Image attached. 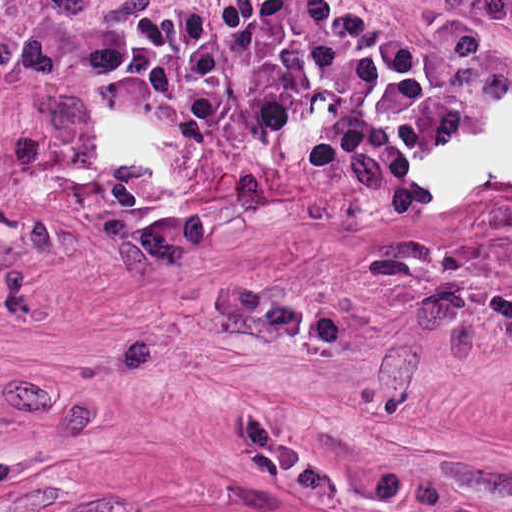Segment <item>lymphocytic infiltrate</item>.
<instances>
[{
  "mask_svg": "<svg viewBox=\"0 0 512 512\" xmlns=\"http://www.w3.org/2000/svg\"><path fill=\"white\" fill-rule=\"evenodd\" d=\"M512 32V0H482ZM23 90L78 84L131 101L159 137L215 148L247 92L284 111L273 148L307 158L325 200L413 218L435 160L463 143L438 73L359 22L344 0H216L133 29L17 36L1 53Z\"/></svg>",
  "mask_w": 512,
  "mask_h": 512,
  "instance_id": "lymphocytic-infiltrate-1",
  "label": "lymphocytic infiltrate"
}]
</instances>
